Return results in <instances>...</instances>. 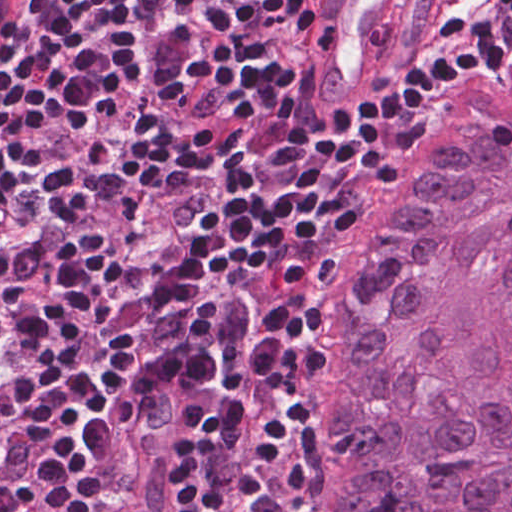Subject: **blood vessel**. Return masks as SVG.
<instances>
[{
  "label": "blood vessel",
  "mask_w": 512,
  "mask_h": 512,
  "mask_svg": "<svg viewBox=\"0 0 512 512\" xmlns=\"http://www.w3.org/2000/svg\"><path fill=\"white\" fill-rule=\"evenodd\" d=\"M400 0H329L313 29L311 79L329 110H350L393 53ZM185 398L168 382L139 398L127 512H182Z\"/></svg>",
  "instance_id": "8fb6f2fc"
}]
</instances>
